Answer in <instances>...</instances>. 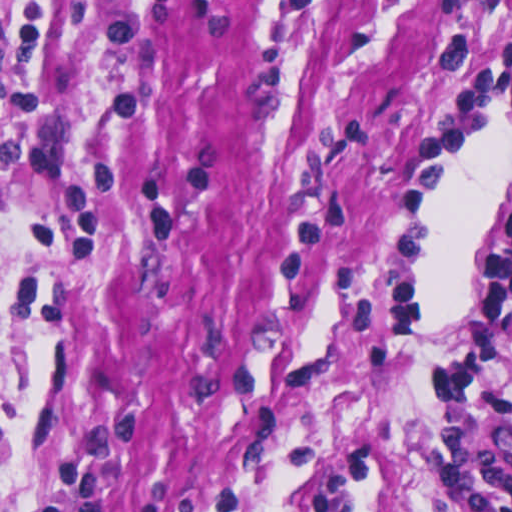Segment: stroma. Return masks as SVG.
I'll return each mask as SVG.
<instances>
[{
	"label": "stroma",
	"mask_w": 512,
	"mask_h": 512,
	"mask_svg": "<svg viewBox=\"0 0 512 512\" xmlns=\"http://www.w3.org/2000/svg\"><path fill=\"white\" fill-rule=\"evenodd\" d=\"M0 0V512H427L403 441L512 211V0Z\"/></svg>",
	"instance_id": "obj_1"
}]
</instances>
